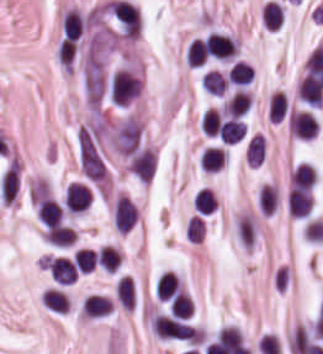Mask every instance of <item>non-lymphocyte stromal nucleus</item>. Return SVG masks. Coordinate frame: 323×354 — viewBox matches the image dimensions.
<instances>
[{
	"mask_svg": "<svg viewBox=\"0 0 323 354\" xmlns=\"http://www.w3.org/2000/svg\"><path fill=\"white\" fill-rule=\"evenodd\" d=\"M150 324L157 335L167 339L200 342V329L174 317L167 315H154Z\"/></svg>",
	"mask_w": 323,
	"mask_h": 354,
	"instance_id": "non-lymphocyte-stromal-nucleus-1",
	"label": "non-lymphocyte stromal nucleus"
},
{
	"mask_svg": "<svg viewBox=\"0 0 323 354\" xmlns=\"http://www.w3.org/2000/svg\"><path fill=\"white\" fill-rule=\"evenodd\" d=\"M78 166L83 178L100 185L105 181L106 167L100 152L87 141L77 145Z\"/></svg>",
	"mask_w": 323,
	"mask_h": 354,
	"instance_id": "non-lymphocyte-stromal-nucleus-2",
	"label": "non-lymphocyte stromal nucleus"
},
{
	"mask_svg": "<svg viewBox=\"0 0 323 354\" xmlns=\"http://www.w3.org/2000/svg\"><path fill=\"white\" fill-rule=\"evenodd\" d=\"M140 92L139 78L123 70L114 71L110 80V100L119 105H127Z\"/></svg>",
	"mask_w": 323,
	"mask_h": 354,
	"instance_id": "non-lymphocyte-stromal-nucleus-3",
	"label": "non-lymphocyte stromal nucleus"
},
{
	"mask_svg": "<svg viewBox=\"0 0 323 354\" xmlns=\"http://www.w3.org/2000/svg\"><path fill=\"white\" fill-rule=\"evenodd\" d=\"M141 125L136 119L128 118L120 127L117 135V148L121 155H129L137 146Z\"/></svg>",
	"mask_w": 323,
	"mask_h": 354,
	"instance_id": "non-lymphocyte-stromal-nucleus-4",
	"label": "non-lymphocyte stromal nucleus"
},
{
	"mask_svg": "<svg viewBox=\"0 0 323 354\" xmlns=\"http://www.w3.org/2000/svg\"><path fill=\"white\" fill-rule=\"evenodd\" d=\"M115 303L124 309L136 306V284L131 276L121 275L114 283Z\"/></svg>",
	"mask_w": 323,
	"mask_h": 354,
	"instance_id": "non-lymphocyte-stromal-nucleus-5",
	"label": "non-lymphocyte stromal nucleus"
}]
</instances>
